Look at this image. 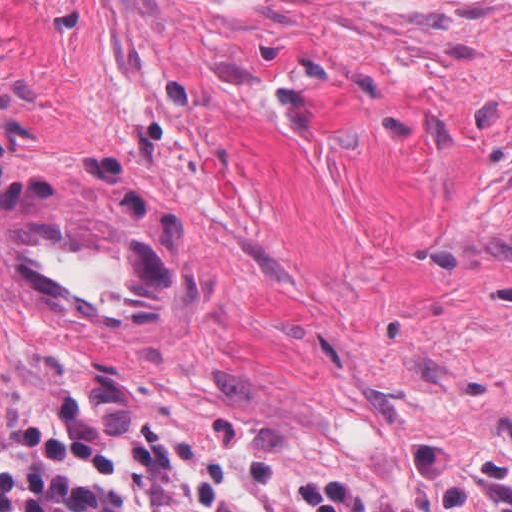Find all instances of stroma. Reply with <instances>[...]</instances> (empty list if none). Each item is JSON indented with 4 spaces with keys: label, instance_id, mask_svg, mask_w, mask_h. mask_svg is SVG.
Segmentation results:
<instances>
[{
    "label": "stroma",
    "instance_id": "35a3bbf8",
    "mask_svg": "<svg viewBox=\"0 0 512 512\" xmlns=\"http://www.w3.org/2000/svg\"><path fill=\"white\" fill-rule=\"evenodd\" d=\"M186 254L156 328L44 310L2 222ZM252 432L309 512H512V0H0V426Z\"/></svg>",
    "mask_w": 512,
    "mask_h": 512
}]
</instances>
